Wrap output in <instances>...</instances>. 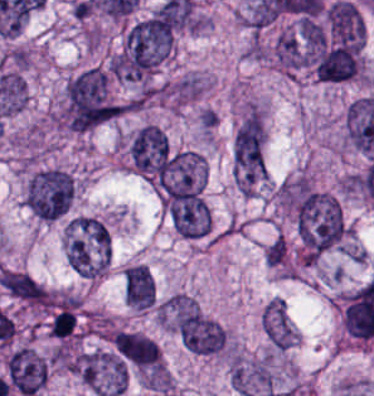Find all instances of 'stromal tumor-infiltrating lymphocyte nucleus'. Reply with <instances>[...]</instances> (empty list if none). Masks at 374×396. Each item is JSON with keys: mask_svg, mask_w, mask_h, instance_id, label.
I'll use <instances>...</instances> for the list:
<instances>
[{"mask_svg": "<svg viewBox=\"0 0 374 396\" xmlns=\"http://www.w3.org/2000/svg\"><path fill=\"white\" fill-rule=\"evenodd\" d=\"M76 328V317L73 307L61 305L51 315L48 322V332L56 337H66Z\"/></svg>", "mask_w": 374, "mask_h": 396, "instance_id": "obj_1", "label": "stromal tumor-infiltrating lymphocyte nucleus"}]
</instances>
